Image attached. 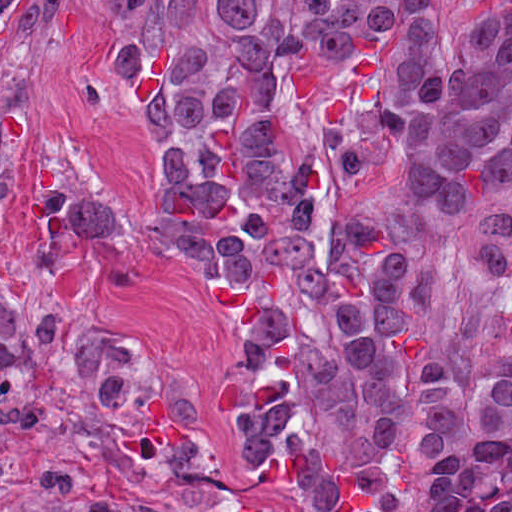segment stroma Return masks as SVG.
Returning a JSON list of instances; mask_svg holds the SVG:
<instances>
[{
    "instance_id": "1",
    "label": "stroma",
    "mask_w": 512,
    "mask_h": 512,
    "mask_svg": "<svg viewBox=\"0 0 512 512\" xmlns=\"http://www.w3.org/2000/svg\"><path fill=\"white\" fill-rule=\"evenodd\" d=\"M172 1L16 0L0 27V193L145 129L113 52Z\"/></svg>"
}]
</instances>
